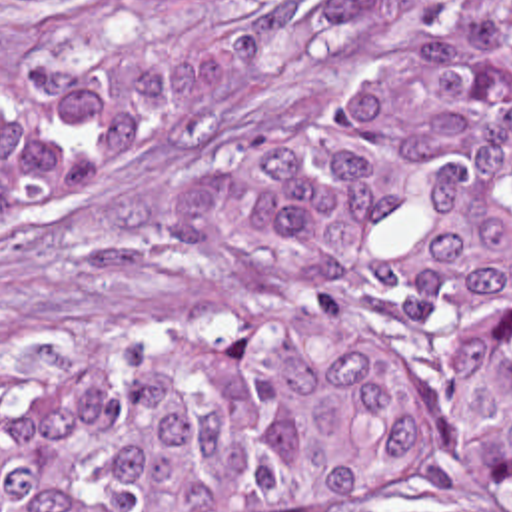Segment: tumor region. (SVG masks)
<instances>
[{
    "mask_svg": "<svg viewBox=\"0 0 512 512\" xmlns=\"http://www.w3.org/2000/svg\"><path fill=\"white\" fill-rule=\"evenodd\" d=\"M233 42L66 46L0 102V224L241 94ZM265 304L0 390V512H261L325 487L512 509V10L267 160Z\"/></svg>",
    "mask_w": 512,
    "mask_h": 512,
    "instance_id": "e687c5a6",
    "label": "tumor region"
}]
</instances>
